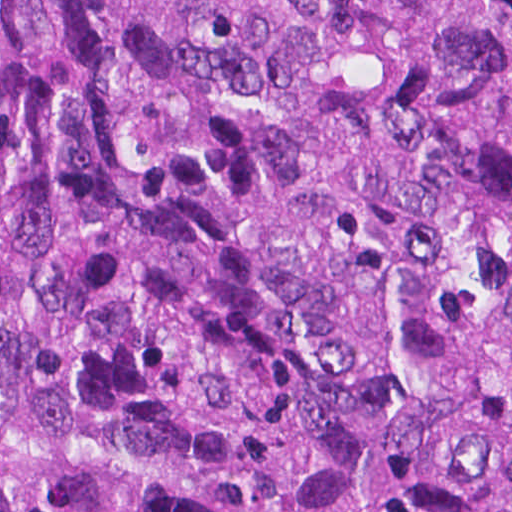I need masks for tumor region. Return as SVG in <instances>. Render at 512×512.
Masks as SVG:
<instances>
[{
  "instance_id": "tumor-region-1",
  "label": "tumor region",
  "mask_w": 512,
  "mask_h": 512,
  "mask_svg": "<svg viewBox=\"0 0 512 512\" xmlns=\"http://www.w3.org/2000/svg\"><path fill=\"white\" fill-rule=\"evenodd\" d=\"M0 512H512V0H0Z\"/></svg>"
}]
</instances>
